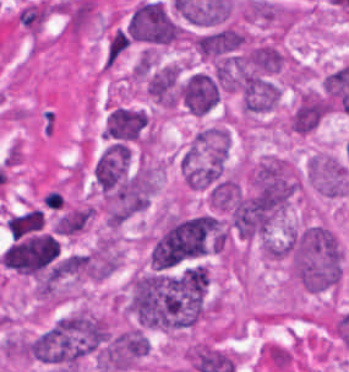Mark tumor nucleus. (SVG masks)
<instances>
[{
	"mask_svg": "<svg viewBox=\"0 0 349 372\" xmlns=\"http://www.w3.org/2000/svg\"><path fill=\"white\" fill-rule=\"evenodd\" d=\"M221 96L219 76L211 69L190 71L177 83L178 103L192 113H205Z\"/></svg>",
	"mask_w": 349,
	"mask_h": 372,
	"instance_id": "tumor-nucleus-5",
	"label": "tumor nucleus"
},
{
	"mask_svg": "<svg viewBox=\"0 0 349 372\" xmlns=\"http://www.w3.org/2000/svg\"><path fill=\"white\" fill-rule=\"evenodd\" d=\"M149 118L143 108L116 105L105 120L102 136L129 141L139 137Z\"/></svg>",
	"mask_w": 349,
	"mask_h": 372,
	"instance_id": "tumor-nucleus-8",
	"label": "tumor nucleus"
},
{
	"mask_svg": "<svg viewBox=\"0 0 349 372\" xmlns=\"http://www.w3.org/2000/svg\"><path fill=\"white\" fill-rule=\"evenodd\" d=\"M104 332L102 315L78 308L33 335L26 352L36 362L71 372L101 347Z\"/></svg>",
	"mask_w": 349,
	"mask_h": 372,
	"instance_id": "tumor-nucleus-2",
	"label": "tumor nucleus"
},
{
	"mask_svg": "<svg viewBox=\"0 0 349 372\" xmlns=\"http://www.w3.org/2000/svg\"><path fill=\"white\" fill-rule=\"evenodd\" d=\"M132 155L128 145H108L94 166L95 180L106 194L128 173Z\"/></svg>",
	"mask_w": 349,
	"mask_h": 372,
	"instance_id": "tumor-nucleus-9",
	"label": "tumor nucleus"
},
{
	"mask_svg": "<svg viewBox=\"0 0 349 372\" xmlns=\"http://www.w3.org/2000/svg\"><path fill=\"white\" fill-rule=\"evenodd\" d=\"M123 310L138 324L175 330L202 315V278L197 263L135 272L123 298Z\"/></svg>",
	"mask_w": 349,
	"mask_h": 372,
	"instance_id": "tumor-nucleus-1",
	"label": "tumor nucleus"
},
{
	"mask_svg": "<svg viewBox=\"0 0 349 372\" xmlns=\"http://www.w3.org/2000/svg\"><path fill=\"white\" fill-rule=\"evenodd\" d=\"M307 173L317 190L328 196H343L349 192L348 161L316 153L307 165Z\"/></svg>",
	"mask_w": 349,
	"mask_h": 372,
	"instance_id": "tumor-nucleus-6",
	"label": "tumor nucleus"
},
{
	"mask_svg": "<svg viewBox=\"0 0 349 372\" xmlns=\"http://www.w3.org/2000/svg\"><path fill=\"white\" fill-rule=\"evenodd\" d=\"M330 109L328 98L321 89H307L298 97L290 113L291 130L296 133L313 131Z\"/></svg>",
	"mask_w": 349,
	"mask_h": 372,
	"instance_id": "tumor-nucleus-7",
	"label": "tumor nucleus"
},
{
	"mask_svg": "<svg viewBox=\"0 0 349 372\" xmlns=\"http://www.w3.org/2000/svg\"><path fill=\"white\" fill-rule=\"evenodd\" d=\"M127 32L132 39L167 44L178 39L181 28L160 0H147L131 12Z\"/></svg>",
	"mask_w": 349,
	"mask_h": 372,
	"instance_id": "tumor-nucleus-4",
	"label": "tumor nucleus"
},
{
	"mask_svg": "<svg viewBox=\"0 0 349 372\" xmlns=\"http://www.w3.org/2000/svg\"><path fill=\"white\" fill-rule=\"evenodd\" d=\"M210 230L208 214L172 218L150 249L151 265L171 266L204 253Z\"/></svg>",
	"mask_w": 349,
	"mask_h": 372,
	"instance_id": "tumor-nucleus-3",
	"label": "tumor nucleus"
},
{
	"mask_svg": "<svg viewBox=\"0 0 349 372\" xmlns=\"http://www.w3.org/2000/svg\"><path fill=\"white\" fill-rule=\"evenodd\" d=\"M118 248L116 237L105 234L85 252L81 271L84 277L102 280L116 269Z\"/></svg>",
	"mask_w": 349,
	"mask_h": 372,
	"instance_id": "tumor-nucleus-10",
	"label": "tumor nucleus"
}]
</instances>
